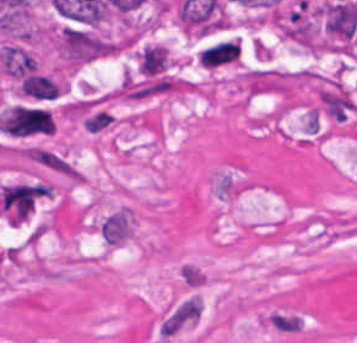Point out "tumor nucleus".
<instances>
[{"label": "tumor nucleus", "mask_w": 357, "mask_h": 343, "mask_svg": "<svg viewBox=\"0 0 357 343\" xmlns=\"http://www.w3.org/2000/svg\"><path fill=\"white\" fill-rule=\"evenodd\" d=\"M197 61L207 69L236 63L230 40L213 43L198 51Z\"/></svg>", "instance_id": "2f306a5c"}]
</instances>
